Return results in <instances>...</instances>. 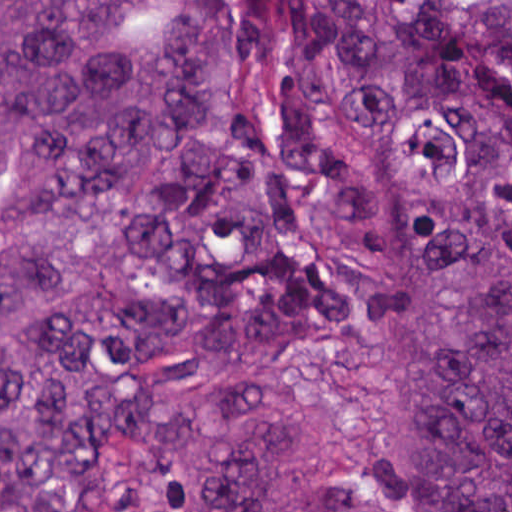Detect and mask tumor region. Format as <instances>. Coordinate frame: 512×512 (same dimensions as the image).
<instances>
[{
  "label": "tumor region",
  "mask_w": 512,
  "mask_h": 512,
  "mask_svg": "<svg viewBox=\"0 0 512 512\" xmlns=\"http://www.w3.org/2000/svg\"><path fill=\"white\" fill-rule=\"evenodd\" d=\"M152 512H294L307 383L352 320L401 435L384 512H512V0H0V512H89L199 375Z\"/></svg>",
  "instance_id": "obj_1"
}]
</instances>
